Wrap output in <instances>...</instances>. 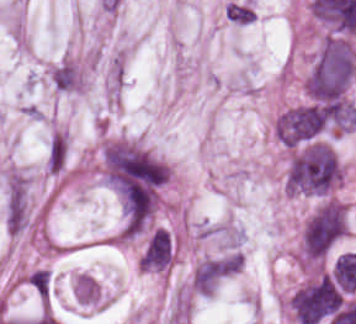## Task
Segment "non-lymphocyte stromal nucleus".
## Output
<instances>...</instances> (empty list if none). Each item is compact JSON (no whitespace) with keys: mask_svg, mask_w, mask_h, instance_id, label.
Here are the masks:
<instances>
[{"mask_svg":"<svg viewBox=\"0 0 356 324\" xmlns=\"http://www.w3.org/2000/svg\"><path fill=\"white\" fill-rule=\"evenodd\" d=\"M66 154L67 141L65 137L61 132H54L47 151V165L49 169L62 170Z\"/></svg>","mask_w":356,"mask_h":324,"instance_id":"non-lymphocyte-stromal-nucleus-3","label":"non-lymphocyte stromal nucleus"},{"mask_svg":"<svg viewBox=\"0 0 356 324\" xmlns=\"http://www.w3.org/2000/svg\"><path fill=\"white\" fill-rule=\"evenodd\" d=\"M5 222L14 234L20 232L25 222V187L20 178H13L9 183Z\"/></svg>","mask_w":356,"mask_h":324,"instance_id":"non-lymphocyte-stromal-nucleus-1","label":"non-lymphocyte stromal nucleus"},{"mask_svg":"<svg viewBox=\"0 0 356 324\" xmlns=\"http://www.w3.org/2000/svg\"><path fill=\"white\" fill-rule=\"evenodd\" d=\"M253 16L252 7L243 1H230L226 5V18L236 23H248Z\"/></svg>","mask_w":356,"mask_h":324,"instance_id":"non-lymphocyte-stromal-nucleus-4","label":"non-lymphocyte stromal nucleus"},{"mask_svg":"<svg viewBox=\"0 0 356 324\" xmlns=\"http://www.w3.org/2000/svg\"><path fill=\"white\" fill-rule=\"evenodd\" d=\"M56 90L74 91L79 87V74L74 63L61 60L50 72Z\"/></svg>","mask_w":356,"mask_h":324,"instance_id":"non-lymphocyte-stromal-nucleus-2","label":"non-lymphocyte stromal nucleus"}]
</instances>
